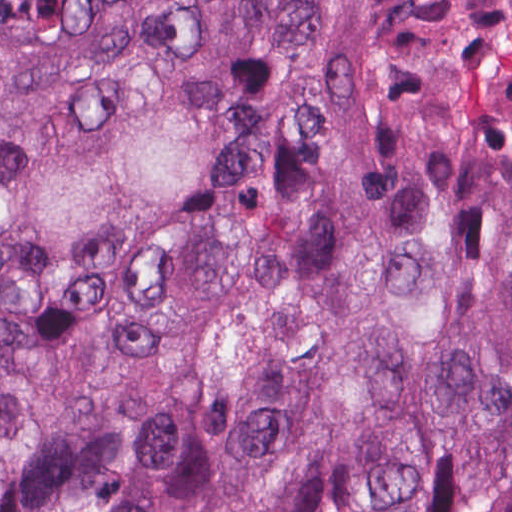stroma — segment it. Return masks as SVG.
<instances>
[{
    "label": "stroma",
    "instance_id": "35a3bbf8",
    "mask_svg": "<svg viewBox=\"0 0 512 512\" xmlns=\"http://www.w3.org/2000/svg\"><path fill=\"white\" fill-rule=\"evenodd\" d=\"M304 74H324L338 79L358 103L364 125L367 171L386 135L431 109H440L367 36L270 22L267 41L246 81L236 113L232 163L158 248L169 238L198 224L219 202L238 174L250 145L275 119L284 94ZM0 127L14 145L33 208L58 250V290L0 306V326H3L66 308L105 287L152 252L119 265H91L76 250L18 110L1 88ZM355 208L348 212L351 232Z\"/></svg>",
    "mask_w": 512,
    "mask_h": 512
}]
</instances>
